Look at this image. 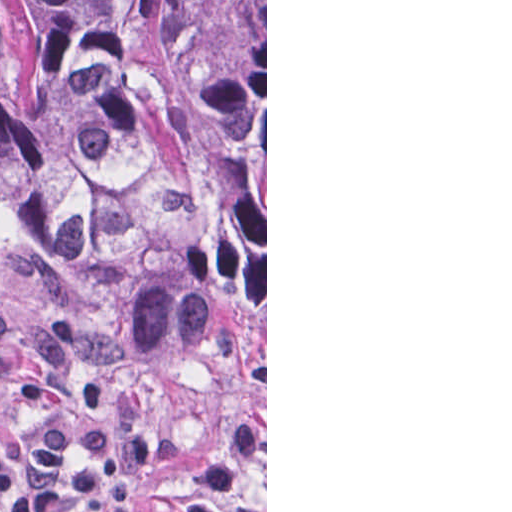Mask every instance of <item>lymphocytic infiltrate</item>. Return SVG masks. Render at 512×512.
I'll use <instances>...</instances> for the list:
<instances>
[{"label":"lymphocytic infiltrate","mask_w":512,"mask_h":512,"mask_svg":"<svg viewBox=\"0 0 512 512\" xmlns=\"http://www.w3.org/2000/svg\"><path fill=\"white\" fill-rule=\"evenodd\" d=\"M73 337L70 320L45 324L33 335V368L14 370L0 308V384L27 403L100 409L103 391L82 386L65 370ZM183 453L182 439L154 432L143 390L129 387L96 419L59 417L38 426L21 455L0 436V511L137 512L138 480L157 462H179ZM249 473H266V431L246 412L201 472L182 512H227V500Z\"/></svg>","instance_id":"obj_1"}]
</instances>
